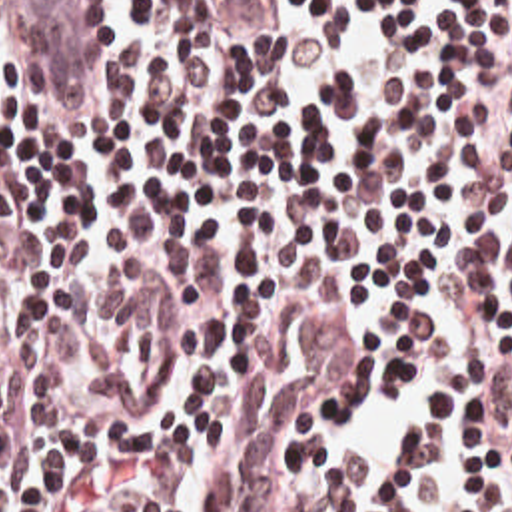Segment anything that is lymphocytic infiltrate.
Here are the masks:
<instances>
[{"label":"lymphocytic infiltrate","mask_w":512,"mask_h":512,"mask_svg":"<svg viewBox=\"0 0 512 512\" xmlns=\"http://www.w3.org/2000/svg\"><path fill=\"white\" fill-rule=\"evenodd\" d=\"M0 512H512V0H0Z\"/></svg>","instance_id":"1"}]
</instances>
